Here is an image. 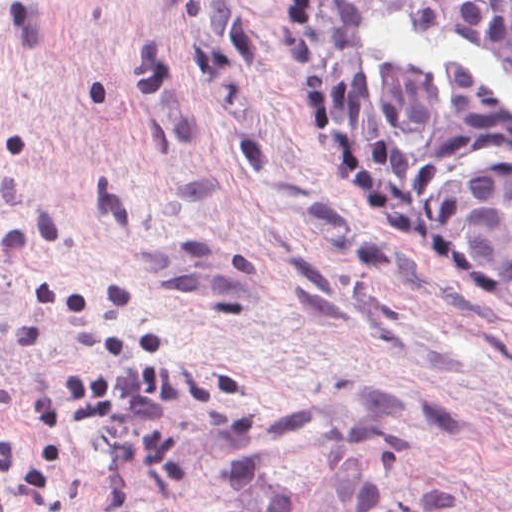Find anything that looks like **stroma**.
I'll return each instance as SVG.
<instances>
[{"mask_svg":"<svg viewBox=\"0 0 512 512\" xmlns=\"http://www.w3.org/2000/svg\"><path fill=\"white\" fill-rule=\"evenodd\" d=\"M0 512H512V296L318 153L289 0H0Z\"/></svg>","mask_w":512,"mask_h":512,"instance_id":"obj_1","label":"stroma"}]
</instances>
